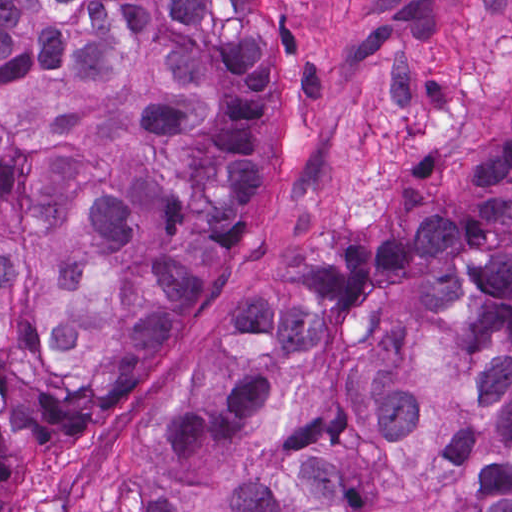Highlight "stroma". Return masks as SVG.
<instances>
[{
  "mask_svg": "<svg viewBox=\"0 0 512 512\" xmlns=\"http://www.w3.org/2000/svg\"><path fill=\"white\" fill-rule=\"evenodd\" d=\"M277 111L262 191L223 274L167 330L133 410L52 466L13 512H150L160 429L198 402L237 318L283 303L322 246L419 228L450 193L474 122L512 111V0H257Z\"/></svg>",
  "mask_w": 512,
  "mask_h": 512,
  "instance_id": "1",
  "label": "stroma"
}]
</instances>
